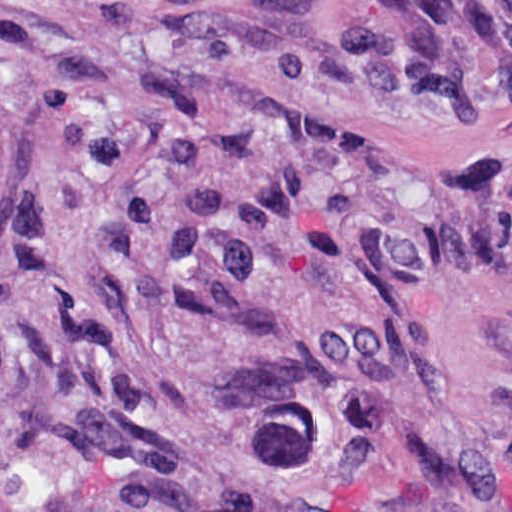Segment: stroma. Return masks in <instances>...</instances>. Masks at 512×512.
<instances>
[{
  "label": "stroma",
  "instance_id": "1",
  "mask_svg": "<svg viewBox=\"0 0 512 512\" xmlns=\"http://www.w3.org/2000/svg\"><path fill=\"white\" fill-rule=\"evenodd\" d=\"M381 1L512 0H0V512H512V79Z\"/></svg>",
  "mask_w": 512,
  "mask_h": 512
}]
</instances>
